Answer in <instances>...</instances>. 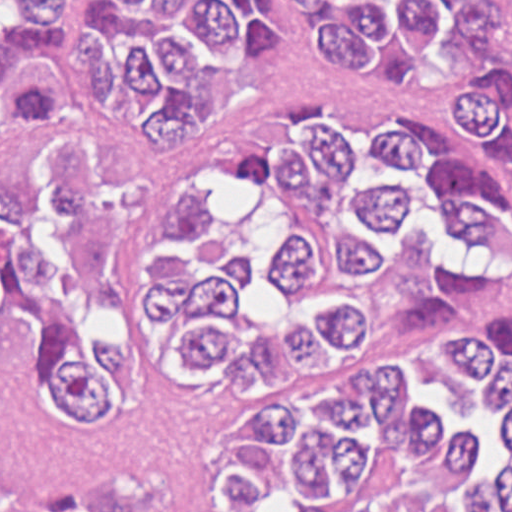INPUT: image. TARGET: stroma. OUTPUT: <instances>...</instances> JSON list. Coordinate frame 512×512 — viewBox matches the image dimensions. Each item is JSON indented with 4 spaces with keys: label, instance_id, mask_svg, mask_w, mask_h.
Segmentation results:
<instances>
[{
    "label": "stroma",
    "instance_id": "obj_1",
    "mask_svg": "<svg viewBox=\"0 0 512 512\" xmlns=\"http://www.w3.org/2000/svg\"><path fill=\"white\" fill-rule=\"evenodd\" d=\"M484 313H512V275L492 302L456 318ZM234 397L226 381L151 383L125 424L78 431L69 418L0 389V512L117 474L135 477L161 512H213L212 448Z\"/></svg>",
    "mask_w": 512,
    "mask_h": 512
}]
</instances>
